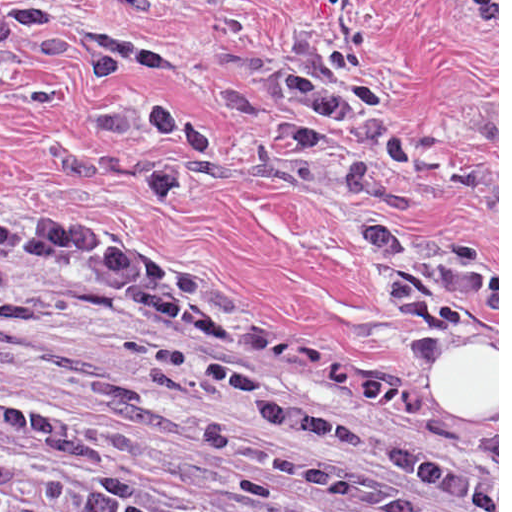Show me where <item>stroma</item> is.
Listing matches in <instances>:
<instances>
[{
    "label": "stroma",
    "instance_id": "stroma-1",
    "mask_svg": "<svg viewBox=\"0 0 512 512\" xmlns=\"http://www.w3.org/2000/svg\"><path fill=\"white\" fill-rule=\"evenodd\" d=\"M89 31L173 47L178 67L122 80L203 121L215 149L177 159L184 194L154 205L144 159L161 137L89 131L100 92L81 63ZM341 38L360 43L396 117L498 182L469 204L431 171H409L407 222L421 241L478 249L492 278L471 323L427 362L408 349L397 301L357 238L390 203L379 159L368 197L349 199L308 158L264 137L284 116L276 87L298 59ZM0 235L145 259L163 291L245 323L280 326L325 365L432 419L436 429L498 433L499 0H176L100 10L73 0H0ZM497 356V416H446L430 394L454 353ZM399 397H397L395 394ZM258 430L255 403L199 378L136 368L110 306L57 274L0 291V460L145 484L161 507L209 498L289 504L300 490L204 444L205 428Z\"/></svg>",
    "mask_w": 512,
    "mask_h": 512
}]
</instances>
